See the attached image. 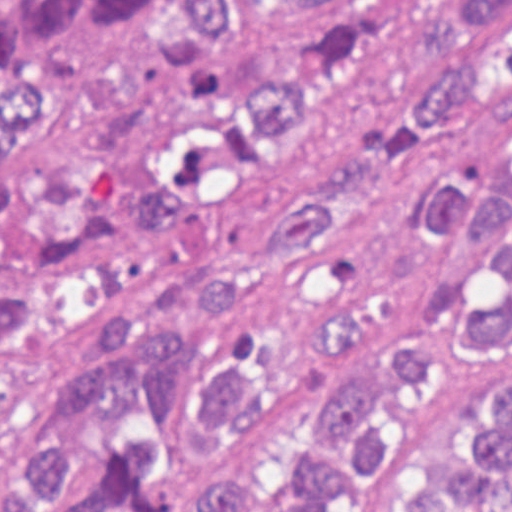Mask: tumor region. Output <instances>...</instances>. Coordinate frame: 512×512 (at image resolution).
<instances>
[{"mask_svg":"<svg viewBox=\"0 0 512 512\" xmlns=\"http://www.w3.org/2000/svg\"><path fill=\"white\" fill-rule=\"evenodd\" d=\"M479 95H512V0H0V512H322L376 465L378 401L461 334L512 322V208L458 178L417 205L441 243L471 222L500 244L498 308L462 284L424 327L324 393L327 446L303 466L228 454L257 403L234 367L203 372L223 444L189 495L136 486L146 438L74 492L85 432L125 417L159 444L212 326L331 235L379 178ZM217 470L272 485L268 499ZM212 472V475L210 476ZM355 512H512V384L471 391L437 442Z\"/></svg>","mask_w":512,"mask_h":512,"instance_id":"1","label":"tumor region"}]
</instances>
